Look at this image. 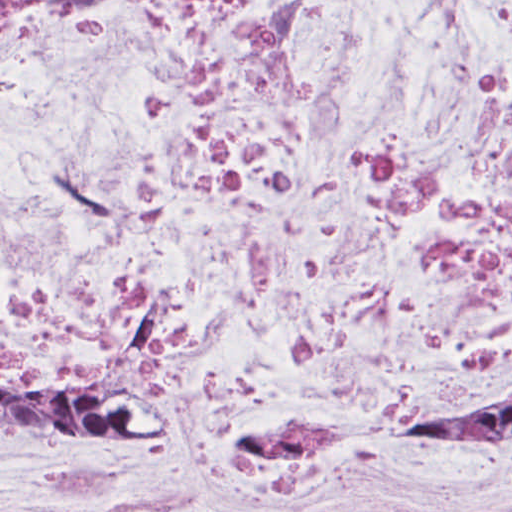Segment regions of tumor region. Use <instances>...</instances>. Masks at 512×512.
Here are the masks:
<instances>
[{"label":"tumor region","mask_w":512,"mask_h":512,"mask_svg":"<svg viewBox=\"0 0 512 512\" xmlns=\"http://www.w3.org/2000/svg\"><path fill=\"white\" fill-rule=\"evenodd\" d=\"M45 424L127 439L151 431L143 418L87 381L0 359V436ZM407 428L512 431V394L430 399L411 414Z\"/></svg>","instance_id":"obj_1"}]
</instances>
